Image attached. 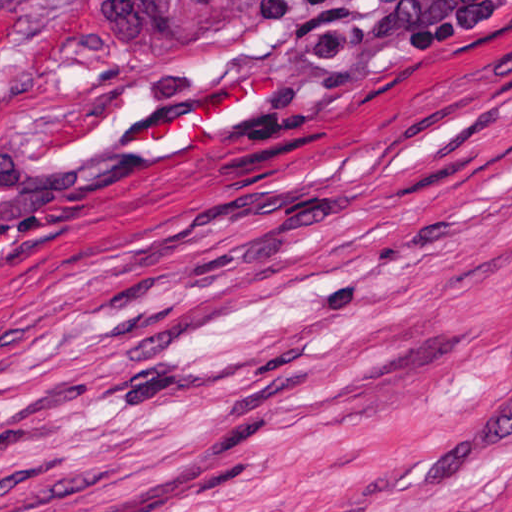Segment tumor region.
<instances>
[{"label": "tumor region", "mask_w": 512, "mask_h": 512, "mask_svg": "<svg viewBox=\"0 0 512 512\" xmlns=\"http://www.w3.org/2000/svg\"><path fill=\"white\" fill-rule=\"evenodd\" d=\"M16 1L56 36L72 73L123 70L173 55L272 36L334 0Z\"/></svg>", "instance_id": "tumor-region-1"}]
</instances>
